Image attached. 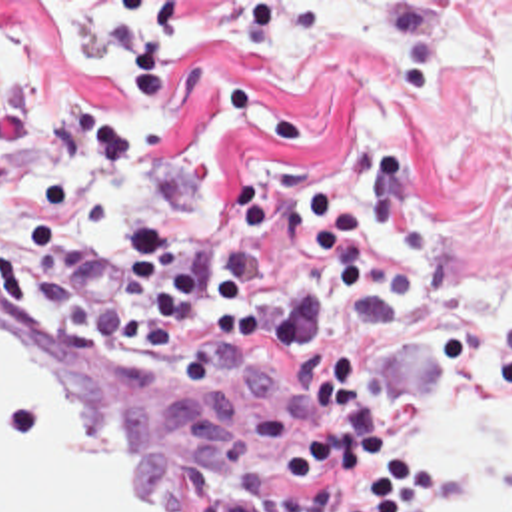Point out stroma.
<instances>
[{
    "mask_svg": "<svg viewBox=\"0 0 512 512\" xmlns=\"http://www.w3.org/2000/svg\"><path fill=\"white\" fill-rule=\"evenodd\" d=\"M455 2L512 0H0L1 286L115 343L125 270L61 274L23 234L43 136L67 112L131 138L83 222L105 244L153 224L185 266H213L241 248L247 188L265 184V280L285 286L307 200L337 192L363 218L367 294L345 305L327 286L313 335L351 357L407 459L437 471L415 512L459 509L471 459L421 433V413L445 379L475 403L512 393V333L479 309V288H512V122L479 66L431 60ZM207 327L187 321L159 351L195 353ZM315 429L229 475L219 512H293L283 455Z\"/></svg>",
    "mask_w": 512,
    "mask_h": 512,
    "instance_id": "1",
    "label": "stroma"
}]
</instances>
